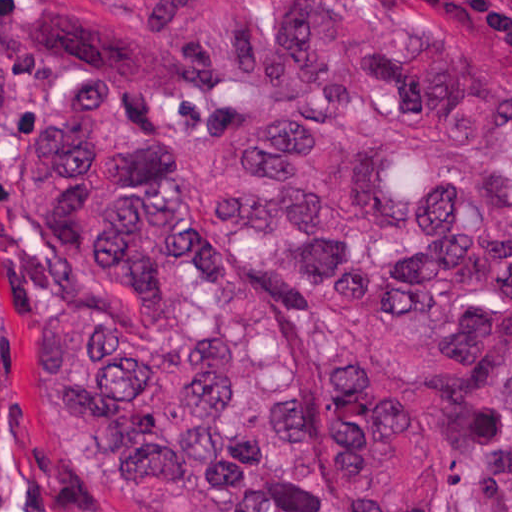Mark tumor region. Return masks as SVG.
<instances>
[{
	"label": "tumor region",
	"instance_id": "e687c5a6",
	"mask_svg": "<svg viewBox=\"0 0 512 512\" xmlns=\"http://www.w3.org/2000/svg\"><path fill=\"white\" fill-rule=\"evenodd\" d=\"M16 1L41 359L108 512H512L510 95L409 0ZM214 91L178 149L143 103Z\"/></svg>",
	"mask_w": 512,
	"mask_h": 512
}]
</instances>
